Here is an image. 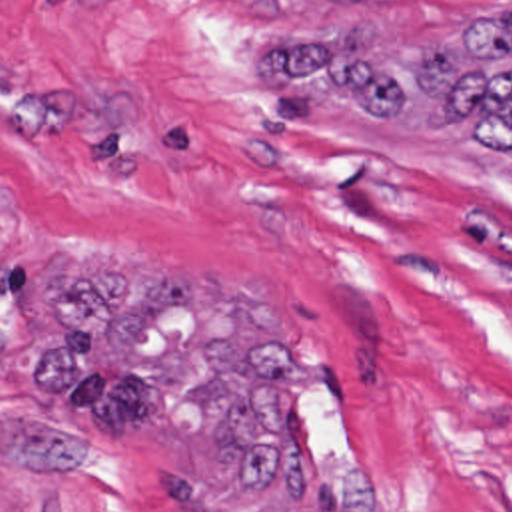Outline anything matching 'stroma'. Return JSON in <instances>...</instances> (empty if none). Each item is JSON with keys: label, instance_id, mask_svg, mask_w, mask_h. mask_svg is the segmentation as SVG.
Masks as SVG:
<instances>
[{"label": "stroma", "instance_id": "stroma-1", "mask_svg": "<svg viewBox=\"0 0 512 512\" xmlns=\"http://www.w3.org/2000/svg\"><path fill=\"white\" fill-rule=\"evenodd\" d=\"M511 5L0 0V412L71 426L33 387L67 253L227 275L323 353L297 426L369 470V512H512V169L455 135L263 93L241 63L353 33L429 51ZM0 512L287 504L131 430L77 468L0 458Z\"/></svg>", "mask_w": 512, "mask_h": 512}]
</instances>
